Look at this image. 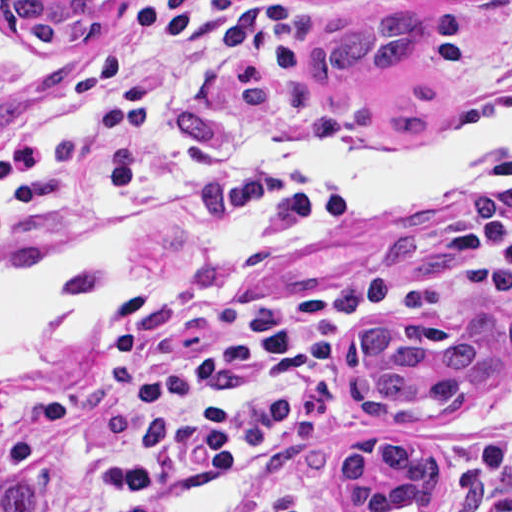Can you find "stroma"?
I'll use <instances>...</instances> for the list:
<instances>
[{"label":"stroma","instance_id":"obj_1","mask_svg":"<svg viewBox=\"0 0 512 512\" xmlns=\"http://www.w3.org/2000/svg\"><path fill=\"white\" fill-rule=\"evenodd\" d=\"M126 1H105L96 31L81 47H44L8 31L0 19V137L44 122L67 87L92 62L109 13ZM397 1L296 0L293 53L301 75L315 42L332 25L354 12ZM430 26L436 49L425 78L440 90L443 104L471 89L483 62L512 32V2L445 5L431 13ZM316 105L323 119L336 125H379L360 99L338 106ZM305 166L307 174L316 178L318 164ZM494 204L512 205V182L463 190L393 217L297 263L222 290L175 318L325 288L376 263L417 278L442 277L480 248L471 231L474 216ZM167 219L210 225L151 197L117 199L92 222ZM328 219L284 213L255 230L320 227ZM487 314L503 317L505 334L510 333L512 284L463 288L407 320L331 323L303 367L299 386L289 396L249 406L244 415L247 427L276 457L309 477L323 512H366L342 497L333 469L338 455L362 440L426 445L444 477V496L434 512H449L473 475L494 483L477 512H512V358L445 419H385L351 401L345 388L350 350L360 332L433 321L469 335L474 319ZM169 320L154 319L113 336L89 356L59 371L38 374L0 397V491L9 479L25 476L37 486V512H165L169 502L184 493L243 475V512H261L266 478L254 467L222 466L191 483L148 486L131 480L121 462L129 428L119 395L123 340Z\"/></svg>","mask_w":512,"mask_h":512}]
</instances>
